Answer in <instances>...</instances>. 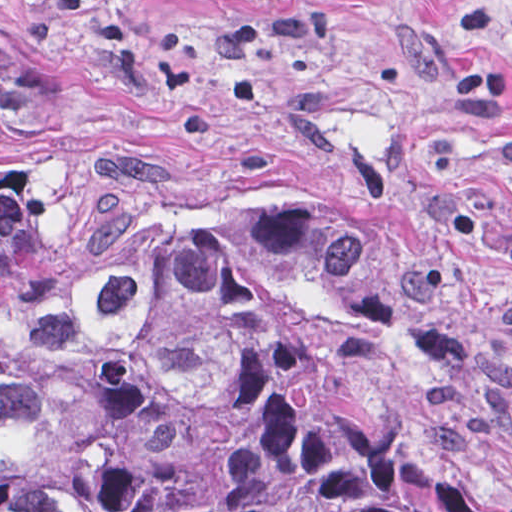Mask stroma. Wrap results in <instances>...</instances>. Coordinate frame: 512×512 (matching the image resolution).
<instances>
[{"mask_svg":"<svg viewBox=\"0 0 512 512\" xmlns=\"http://www.w3.org/2000/svg\"><path fill=\"white\" fill-rule=\"evenodd\" d=\"M467 7L491 11L512 97V0H0V32L57 56L192 192L289 196L361 231L416 317L339 333L349 389L512 510V112L449 83Z\"/></svg>","mask_w":512,"mask_h":512,"instance_id":"35a3bbf8","label":"stroma"}]
</instances>
